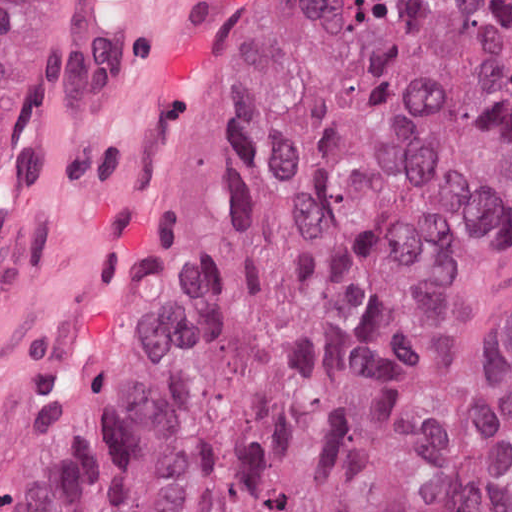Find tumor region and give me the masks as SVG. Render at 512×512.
I'll list each match as a JSON object with an SVG mask.
<instances>
[{"mask_svg":"<svg viewBox=\"0 0 512 512\" xmlns=\"http://www.w3.org/2000/svg\"><path fill=\"white\" fill-rule=\"evenodd\" d=\"M45 24L0 0V218ZM511 208L512 0H268L187 298L56 512H512L420 333Z\"/></svg>","mask_w":512,"mask_h":512,"instance_id":"e687c5a6","label":"tumor region"}]
</instances>
